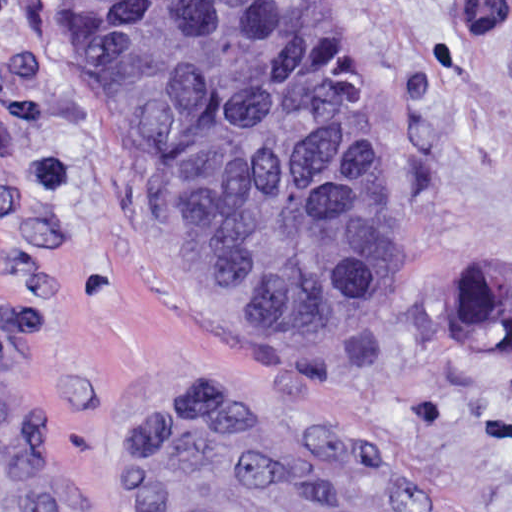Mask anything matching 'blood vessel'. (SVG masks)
I'll list each match as a JSON object with an SVG mask.
<instances>
[{
    "instance_id": "obj_1",
    "label": "blood vessel",
    "mask_w": 512,
    "mask_h": 512,
    "mask_svg": "<svg viewBox=\"0 0 512 512\" xmlns=\"http://www.w3.org/2000/svg\"><path fill=\"white\" fill-rule=\"evenodd\" d=\"M155 512H432L312 418L213 400L152 442Z\"/></svg>"
}]
</instances>
